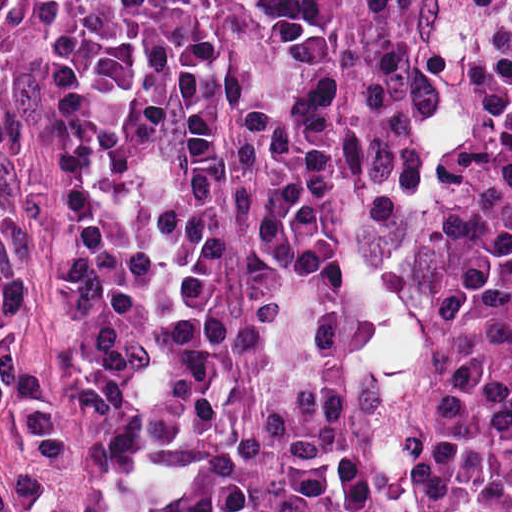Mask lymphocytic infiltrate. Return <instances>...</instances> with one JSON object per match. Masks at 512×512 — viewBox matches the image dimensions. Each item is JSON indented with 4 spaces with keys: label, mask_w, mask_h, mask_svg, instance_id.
<instances>
[{
    "label": "lymphocytic infiltrate",
    "mask_w": 512,
    "mask_h": 512,
    "mask_svg": "<svg viewBox=\"0 0 512 512\" xmlns=\"http://www.w3.org/2000/svg\"><path fill=\"white\" fill-rule=\"evenodd\" d=\"M424 0H55L63 432L0 328V512H366L340 288L399 192ZM54 0H0V133ZM437 512H512V0H473L391 233Z\"/></svg>",
    "instance_id": "f902f5d3"
}]
</instances>
